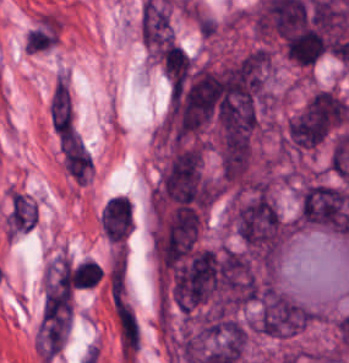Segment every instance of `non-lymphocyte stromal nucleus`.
<instances>
[{
    "mask_svg": "<svg viewBox=\"0 0 349 363\" xmlns=\"http://www.w3.org/2000/svg\"><path fill=\"white\" fill-rule=\"evenodd\" d=\"M48 121L60 141L75 125V105L68 75L61 67L56 70L48 98Z\"/></svg>",
    "mask_w": 349,
    "mask_h": 363,
    "instance_id": "non-lymphocyte-stromal-nucleus-1",
    "label": "non-lymphocyte stromal nucleus"
}]
</instances>
